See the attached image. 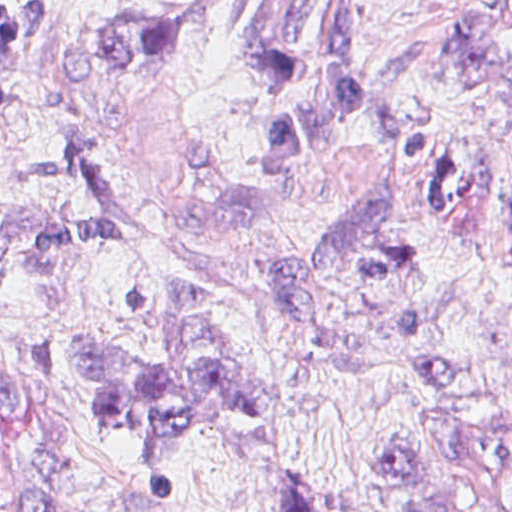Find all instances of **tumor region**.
Returning a JSON list of instances; mask_svg holds the SVG:
<instances>
[{
	"mask_svg": "<svg viewBox=\"0 0 512 512\" xmlns=\"http://www.w3.org/2000/svg\"><path fill=\"white\" fill-rule=\"evenodd\" d=\"M512 27V0H495ZM28 42L0 0V96ZM131 68H230L263 86L280 131V164L334 138L358 114L371 61V0H159L126 38ZM512 237V192L504 211ZM104 209L0 220V301L36 320L77 391L122 434L141 470L163 485L197 441L252 410L254 393L230 333L192 285L175 289L169 346L112 350L85 333V280L102 245ZM385 512H512V477L425 465L378 449Z\"/></svg>",
	"mask_w": 512,
	"mask_h": 512,
	"instance_id": "1",
	"label": "tumor region"
}]
</instances>
